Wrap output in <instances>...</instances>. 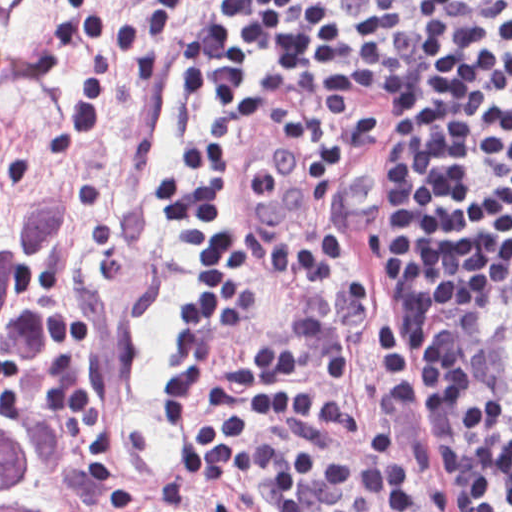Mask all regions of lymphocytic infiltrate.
<instances>
[{"label": "lymphocytic infiltrate", "mask_w": 512, "mask_h": 512, "mask_svg": "<svg viewBox=\"0 0 512 512\" xmlns=\"http://www.w3.org/2000/svg\"><path fill=\"white\" fill-rule=\"evenodd\" d=\"M102 0L60 7L45 35L55 72L81 59L51 159L87 150L128 80L164 81L171 48L216 0ZM197 128L151 183L161 224L189 280L175 307L174 351L158 372L173 447L165 512L252 476L270 512H413L394 438L351 447L264 438L209 355L254 297L257 244L233 194V104L306 65L357 64L390 75L406 104V319L391 304L422 409L441 512H512V271L452 317L512 257V0H239L182 34ZM452 317V318H451Z\"/></svg>", "instance_id": "lymphocytic-infiltrate-1"}]
</instances>
